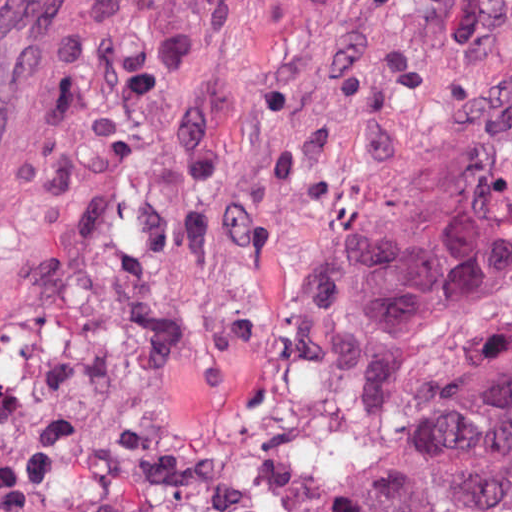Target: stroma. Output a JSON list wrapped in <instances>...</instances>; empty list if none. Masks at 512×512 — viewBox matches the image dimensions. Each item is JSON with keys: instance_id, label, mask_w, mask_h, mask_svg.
<instances>
[{"instance_id": "1", "label": "stroma", "mask_w": 512, "mask_h": 512, "mask_svg": "<svg viewBox=\"0 0 512 512\" xmlns=\"http://www.w3.org/2000/svg\"><path fill=\"white\" fill-rule=\"evenodd\" d=\"M512 99V0H0V512H354L336 317Z\"/></svg>"}]
</instances>
